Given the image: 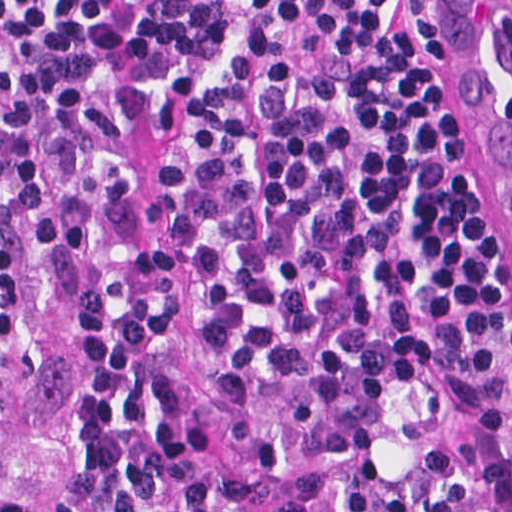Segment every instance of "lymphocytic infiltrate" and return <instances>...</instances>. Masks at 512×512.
Returning <instances> with one entry per match:
<instances>
[{"label": "lymphocytic infiltrate", "instance_id": "lymphocytic-infiltrate-1", "mask_svg": "<svg viewBox=\"0 0 512 512\" xmlns=\"http://www.w3.org/2000/svg\"><path fill=\"white\" fill-rule=\"evenodd\" d=\"M213 329L324 389L335 512H512V249L445 0H0V356L85 322L104 512H249L198 405L142 162ZM0 512H59L0 477Z\"/></svg>", "mask_w": 512, "mask_h": 512}]
</instances>
